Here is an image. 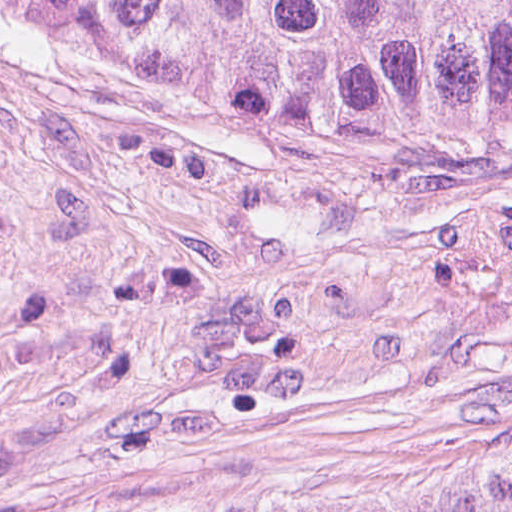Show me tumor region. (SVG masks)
Masks as SVG:
<instances>
[{"instance_id":"obj_1","label":"tumor region","mask_w":512,"mask_h":512,"mask_svg":"<svg viewBox=\"0 0 512 512\" xmlns=\"http://www.w3.org/2000/svg\"><path fill=\"white\" fill-rule=\"evenodd\" d=\"M0 20L246 115L512 148V0H0ZM175 512H512V446Z\"/></svg>"}]
</instances>
